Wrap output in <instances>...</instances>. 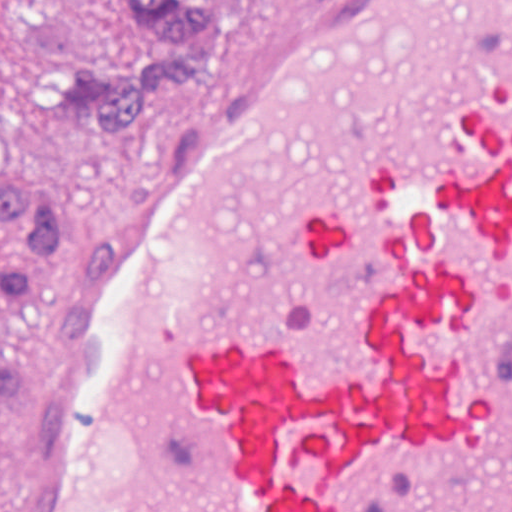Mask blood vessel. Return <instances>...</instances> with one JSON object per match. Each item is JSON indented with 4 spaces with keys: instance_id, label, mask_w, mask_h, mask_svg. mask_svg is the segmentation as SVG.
Wrapping results in <instances>:
<instances>
[{
    "instance_id": "obj_1",
    "label": "blood vessel",
    "mask_w": 512,
    "mask_h": 512,
    "mask_svg": "<svg viewBox=\"0 0 512 512\" xmlns=\"http://www.w3.org/2000/svg\"><path fill=\"white\" fill-rule=\"evenodd\" d=\"M0 512H512V0H273L114 177Z\"/></svg>"
}]
</instances>
